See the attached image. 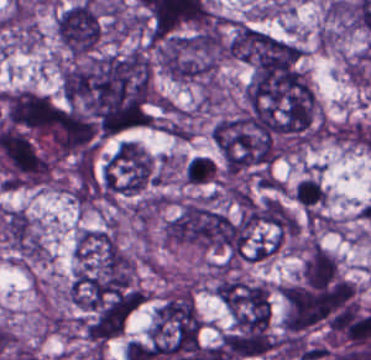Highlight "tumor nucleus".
Wrapping results in <instances>:
<instances>
[{
    "mask_svg": "<svg viewBox=\"0 0 371 360\" xmlns=\"http://www.w3.org/2000/svg\"><path fill=\"white\" fill-rule=\"evenodd\" d=\"M159 67L180 82H209L224 56L217 28L208 27L167 35L154 45Z\"/></svg>",
    "mask_w": 371,
    "mask_h": 360,
    "instance_id": "2f306a5c",
    "label": "tumor nucleus"
},
{
    "mask_svg": "<svg viewBox=\"0 0 371 360\" xmlns=\"http://www.w3.org/2000/svg\"><path fill=\"white\" fill-rule=\"evenodd\" d=\"M200 329L192 289L170 288L153 308L146 336L159 350L185 351L198 345Z\"/></svg>",
    "mask_w": 371,
    "mask_h": 360,
    "instance_id": "8643909e",
    "label": "tumor nucleus"
},
{
    "mask_svg": "<svg viewBox=\"0 0 371 360\" xmlns=\"http://www.w3.org/2000/svg\"><path fill=\"white\" fill-rule=\"evenodd\" d=\"M212 290L230 315L238 321H269V284L235 273H222Z\"/></svg>",
    "mask_w": 371,
    "mask_h": 360,
    "instance_id": "5ab6c2c4",
    "label": "tumor nucleus"
},
{
    "mask_svg": "<svg viewBox=\"0 0 371 360\" xmlns=\"http://www.w3.org/2000/svg\"><path fill=\"white\" fill-rule=\"evenodd\" d=\"M55 34L68 55H88L102 38L103 23L93 3L81 0L56 14Z\"/></svg>",
    "mask_w": 371,
    "mask_h": 360,
    "instance_id": "2cbd58db",
    "label": "tumor nucleus"
},
{
    "mask_svg": "<svg viewBox=\"0 0 371 360\" xmlns=\"http://www.w3.org/2000/svg\"><path fill=\"white\" fill-rule=\"evenodd\" d=\"M221 341L236 360L269 356L275 350L271 316L236 321L221 335Z\"/></svg>",
    "mask_w": 371,
    "mask_h": 360,
    "instance_id": "3d1891a8",
    "label": "tumor nucleus"
},
{
    "mask_svg": "<svg viewBox=\"0 0 371 360\" xmlns=\"http://www.w3.org/2000/svg\"><path fill=\"white\" fill-rule=\"evenodd\" d=\"M152 158L130 140L110 152L105 169L125 190H137L147 179Z\"/></svg>",
    "mask_w": 371,
    "mask_h": 360,
    "instance_id": "2083b535",
    "label": "tumor nucleus"
},
{
    "mask_svg": "<svg viewBox=\"0 0 371 360\" xmlns=\"http://www.w3.org/2000/svg\"><path fill=\"white\" fill-rule=\"evenodd\" d=\"M298 278L309 288H327L340 279L338 261L320 243L308 240L300 248Z\"/></svg>",
    "mask_w": 371,
    "mask_h": 360,
    "instance_id": "8087334f",
    "label": "tumor nucleus"
}]
</instances>
